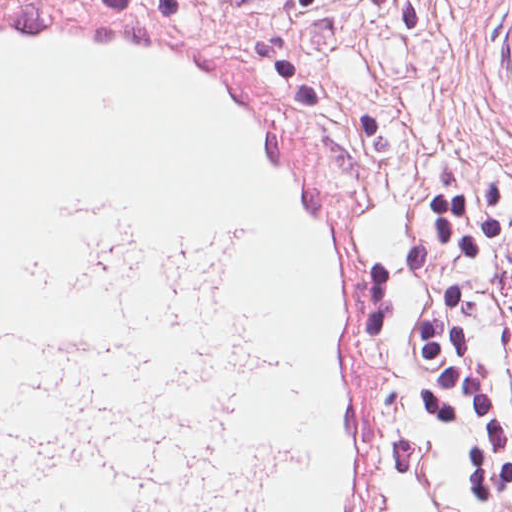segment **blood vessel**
I'll list each match as a JSON object with an SVG mask.
<instances>
[{
  "instance_id": "1",
  "label": "blood vessel",
  "mask_w": 512,
  "mask_h": 512,
  "mask_svg": "<svg viewBox=\"0 0 512 512\" xmlns=\"http://www.w3.org/2000/svg\"><path fill=\"white\" fill-rule=\"evenodd\" d=\"M130 5H0V303L53 305L76 192L240 233L306 414L270 512H378L359 283L388 227L327 126L226 46Z\"/></svg>"
}]
</instances>
